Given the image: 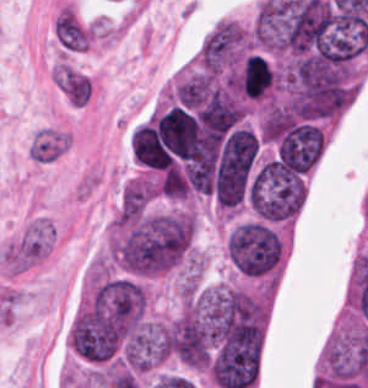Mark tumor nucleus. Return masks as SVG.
I'll return each instance as SVG.
<instances>
[{
	"label": "tumor nucleus",
	"instance_id": "1",
	"mask_svg": "<svg viewBox=\"0 0 368 388\" xmlns=\"http://www.w3.org/2000/svg\"><path fill=\"white\" fill-rule=\"evenodd\" d=\"M156 185L149 175L131 178L121 191L123 211H143L155 195Z\"/></svg>",
	"mask_w": 368,
	"mask_h": 388
}]
</instances>
